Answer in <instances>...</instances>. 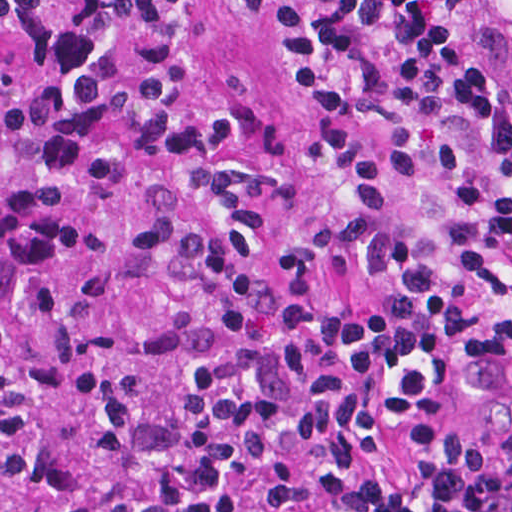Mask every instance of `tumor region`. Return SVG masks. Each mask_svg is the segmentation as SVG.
I'll list each match as a JSON object with an SVG mask.
<instances>
[{
    "instance_id": "tumor-region-1",
    "label": "tumor region",
    "mask_w": 512,
    "mask_h": 512,
    "mask_svg": "<svg viewBox=\"0 0 512 512\" xmlns=\"http://www.w3.org/2000/svg\"><path fill=\"white\" fill-rule=\"evenodd\" d=\"M346 354L302 274L145 137L0 69V512Z\"/></svg>"
}]
</instances>
